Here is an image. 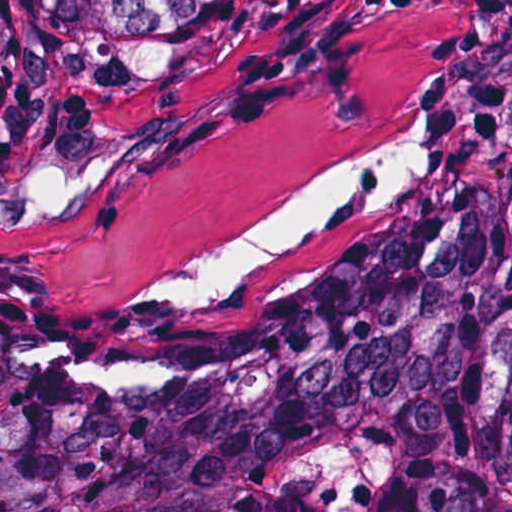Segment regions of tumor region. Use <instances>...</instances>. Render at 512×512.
<instances>
[{
    "label": "tumor region",
    "mask_w": 512,
    "mask_h": 512,
    "mask_svg": "<svg viewBox=\"0 0 512 512\" xmlns=\"http://www.w3.org/2000/svg\"><path fill=\"white\" fill-rule=\"evenodd\" d=\"M255 1L0 0V155ZM0 512H512V177L190 306L0 294Z\"/></svg>",
    "instance_id": "1"
}]
</instances>
